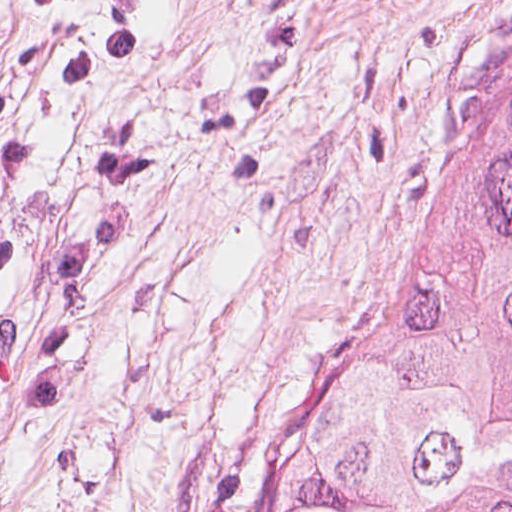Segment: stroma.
Instances as JSON below:
<instances>
[{
    "mask_svg": "<svg viewBox=\"0 0 512 512\" xmlns=\"http://www.w3.org/2000/svg\"><path fill=\"white\" fill-rule=\"evenodd\" d=\"M512 123V0H0V512H269Z\"/></svg>",
    "mask_w": 512,
    "mask_h": 512,
    "instance_id": "obj_1",
    "label": "stroma"
}]
</instances>
